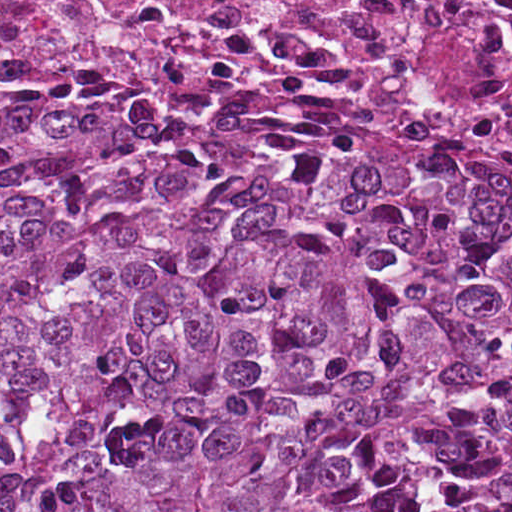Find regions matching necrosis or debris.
Returning <instances> with one entry per match:
<instances>
[{"mask_svg": "<svg viewBox=\"0 0 512 512\" xmlns=\"http://www.w3.org/2000/svg\"><path fill=\"white\" fill-rule=\"evenodd\" d=\"M14 68L303 76L512 145V0H0Z\"/></svg>", "mask_w": 512, "mask_h": 512, "instance_id": "1", "label": "necrosis or debris"}]
</instances>
